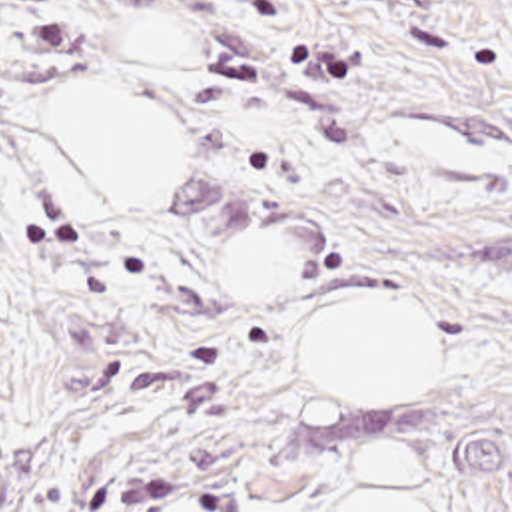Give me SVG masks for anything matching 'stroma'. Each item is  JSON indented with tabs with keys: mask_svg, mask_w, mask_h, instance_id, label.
I'll list each match as a JSON object with an SVG mask.
<instances>
[{
	"mask_svg": "<svg viewBox=\"0 0 512 512\" xmlns=\"http://www.w3.org/2000/svg\"><path fill=\"white\" fill-rule=\"evenodd\" d=\"M91 79L185 115L159 203H79L41 117ZM259 229L295 279L225 293ZM352 297L430 313L420 400L304 388L297 329ZM0 438L19 512H338L370 446L512 512V0H0Z\"/></svg>",
	"mask_w": 512,
	"mask_h": 512,
	"instance_id": "35a3bbf8",
	"label": "stroma"
}]
</instances>
